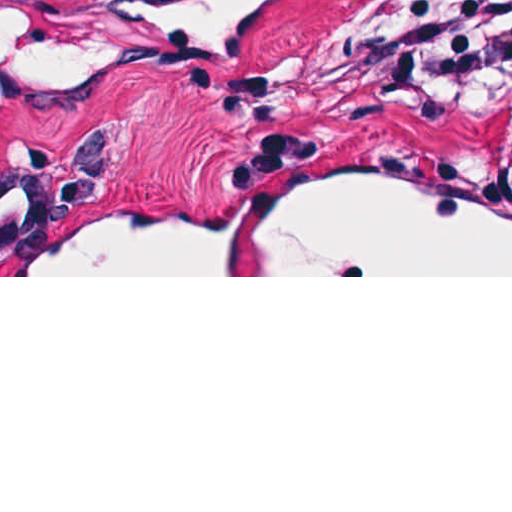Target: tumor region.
<instances>
[{
    "mask_svg": "<svg viewBox=\"0 0 512 512\" xmlns=\"http://www.w3.org/2000/svg\"><path fill=\"white\" fill-rule=\"evenodd\" d=\"M477 0H402L370 35L381 68L401 83L477 106H507L490 138L495 165L512 174L505 131L512 117V37L473 61L456 78L435 82L422 72V36Z\"/></svg>",
    "mask_w": 512,
    "mask_h": 512,
    "instance_id": "obj_1",
    "label": "tumor region"
}]
</instances>
